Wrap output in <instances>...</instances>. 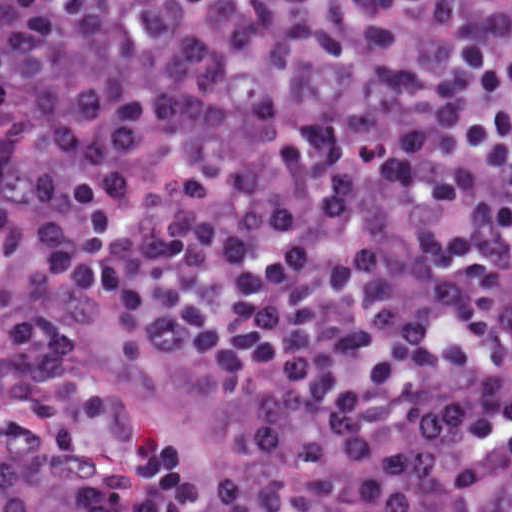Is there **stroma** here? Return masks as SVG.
<instances>
[{
  "mask_svg": "<svg viewBox=\"0 0 512 512\" xmlns=\"http://www.w3.org/2000/svg\"><path fill=\"white\" fill-rule=\"evenodd\" d=\"M110 310L77 289H62L63 318L74 332L71 366L76 383L110 397L151 428L180 464L204 479L228 478L242 458L244 421L218 374L167 361L125 363L118 341L98 328Z\"/></svg>",
  "mask_w": 512,
  "mask_h": 512,
  "instance_id": "1",
  "label": "stroma"
}]
</instances>
